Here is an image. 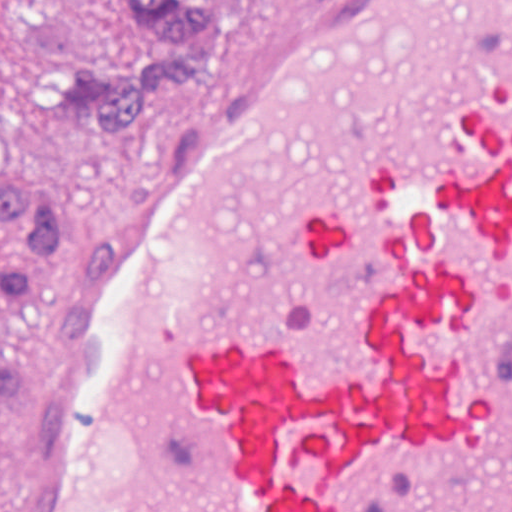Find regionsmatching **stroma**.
I'll use <instances>...</instances> for the list:
<instances>
[{
    "label": "stroma",
    "mask_w": 512,
    "mask_h": 512,
    "mask_svg": "<svg viewBox=\"0 0 512 512\" xmlns=\"http://www.w3.org/2000/svg\"><path fill=\"white\" fill-rule=\"evenodd\" d=\"M225 38L197 83L164 103L142 133L100 137L98 126L69 107L32 104L15 38L0 4V189L39 187L62 207L71 248L35 269L39 293L25 313L0 304V366H14L0 401V476L18 439L24 405L43 359L72 308L86 229L112 179L185 129L254 22L273 0H224Z\"/></svg>",
    "instance_id": "obj_1"
}]
</instances>
